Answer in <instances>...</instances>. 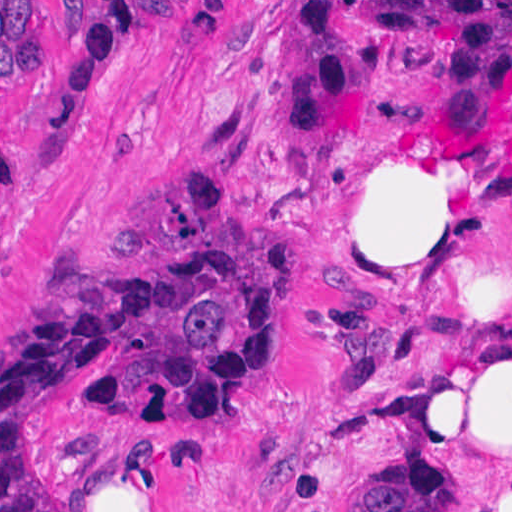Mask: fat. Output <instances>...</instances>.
<instances>
[{"instance_id":"obj_1","label":"fat","mask_w":512,"mask_h":512,"mask_svg":"<svg viewBox=\"0 0 512 512\" xmlns=\"http://www.w3.org/2000/svg\"><path fill=\"white\" fill-rule=\"evenodd\" d=\"M493 196L380 162L325 196L303 269L309 298H439L473 308L419 352L413 383L455 444L498 478L483 512H512V282L491 250Z\"/></svg>"}]
</instances>
